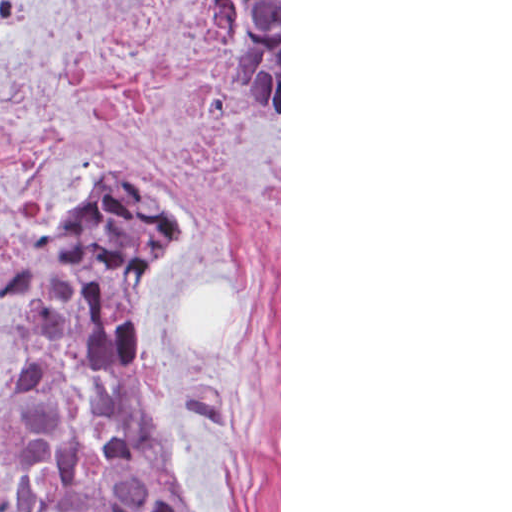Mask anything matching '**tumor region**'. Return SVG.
<instances>
[{
  "label": "tumor region",
  "instance_id": "e687c5a6",
  "mask_svg": "<svg viewBox=\"0 0 512 512\" xmlns=\"http://www.w3.org/2000/svg\"><path fill=\"white\" fill-rule=\"evenodd\" d=\"M222 64L279 128V1H210ZM32 1H0V32ZM143 175L0 222V306L26 317L34 374L0 402V512H196L146 403L130 301L185 226Z\"/></svg>",
  "mask_w": 512,
  "mask_h": 512
}]
</instances>
